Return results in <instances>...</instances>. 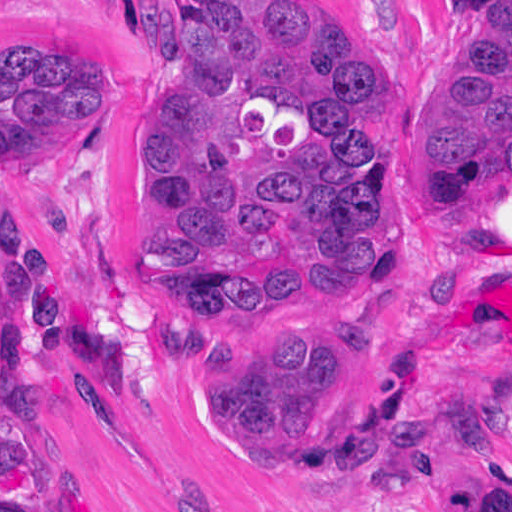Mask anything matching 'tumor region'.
<instances>
[{
	"instance_id": "1",
	"label": "tumor region",
	"mask_w": 512,
	"mask_h": 512,
	"mask_svg": "<svg viewBox=\"0 0 512 512\" xmlns=\"http://www.w3.org/2000/svg\"><path fill=\"white\" fill-rule=\"evenodd\" d=\"M183 63L139 174V256L169 319L254 299L378 283L390 251L393 144L372 146L377 73L304 0H176ZM115 81L83 56L31 44L1 55V165L99 124ZM420 151L427 191L443 164L512 171V7L442 81ZM1 344L28 376L99 383L118 402L164 379L136 311L59 234L1 248ZM337 332H247L194 359L189 415L209 442L349 494H411L454 438L421 405L346 456L316 449ZM490 419L512 433V387ZM453 512H512V463L480 466Z\"/></svg>"
}]
</instances>
